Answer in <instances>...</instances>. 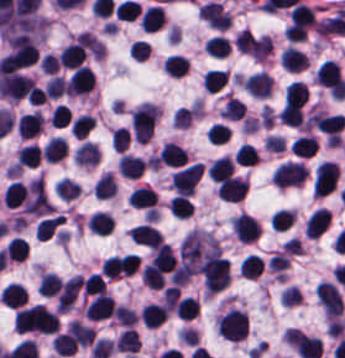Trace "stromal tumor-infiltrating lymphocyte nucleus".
<instances>
[{
	"label": "stromal tumor-infiltrating lymphocyte nucleus",
	"mask_w": 345,
	"mask_h": 358,
	"mask_svg": "<svg viewBox=\"0 0 345 358\" xmlns=\"http://www.w3.org/2000/svg\"><path fill=\"white\" fill-rule=\"evenodd\" d=\"M219 332L230 340L241 341L248 335L247 314L240 309H232L219 319Z\"/></svg>",
	"instance_id": "bc302bb0"
},
{
	"label": "stromal tumor-infiltrating lymphocyte nucleus",
	"mask_w": 345,
	"mask_h": 358,
	"mask_svg": "<svg viewBox=\"0 0 345 358\" xmlns=\"http://www.w3.org/2000/svg\"><path fill=\"white\" fill-rule=\"evenodd\" d=\"M156 115L154 104L142 103L134 112L131 118L133 138L146 142L153 132Z\"/></svg>",
	"instance_id": "52c7bb5b"
},
{
	"label": "stromal tumor-infiltrating lymphocyte nucleus",
	"mask_w": 345,
	"mask_h": 358,
	"mask_svg": "<svg viewBox=\"0 0 345 358\" xmlns=\"http://www.w3.org/2000/svg\"><path fill=\"white\" fill-rule=\"evenodd\" d=\"M204 170L205 166L200 163L179 169L172 179L177 195H192Z\"/></svg>",
	"instance_id": "3290ff9b"
},
{
	"label": "stromal tumor-infiltrating lymphocyte nucleus",
	"mask_w": 345,
	"mask_h": 358,
	"mask_svg": "<svg viewBox=\"0 0 345 358\" xmlns=\"http://www.w3.org/2000/svg\"><path fill=\"white\" fill-rule=\"evenodd\" d=\"M307 173L300 163L289 160L277 166L272 182L278 187L295 186L304 181Z\"/></svg>",
	"instance_id": "abfb95fc"
},
{
	"label": "stromal tumor-infiltrating lymphocyte nucleus",
	"mask_w": 345,
	"mask_h": 358,
	"mask_svg": "<svg viewBox=\"0 0 345 358\" xmlns=\"http://www.w3.org/2000/svg\"><path fill=\"white\" fill-rule=\"evenodd\" d=\"M318 301L325 312L339 316L342 311V297L334 283L322 281L315 289Z\"/></svg>",
	"instance_id": "9ea309e8"
},
{
	"label": "stromal tumor-infiltrating lymphocyte nucleus",
	"mask_w": 345,
	"mask_h": 358,
	"mask_svg": "<svg viewBox=\"0 0 345 358\" xmlns=\"http://www.w3.org/2000/svg\"><path fill=\"white\" fill-rule=\"evenodd\" d=\"M116 312V304L109 294L98 293L87 304L85 315L89 319H102Z\"/></svg>",
	"instance_id": "f3e2335f"
},
{
	"label": "stromal tumor-infiltrating lymphocyte nucleus",
	"mask_w": 345,
	"mask_h": 358,
	"mask_svg": "<svg viewBox=\"0 0 345 358\" xmlns=\"http://www.w3.org/2000/svg\"><path fill=\"white\" fill-rule=\"evenodd\" d=\"M232 227L241 241H254L262 232L261 227L251 215L241 214L234 217Z\"/></svg>",
	"instance_id": "4f13568d"
},
{
	"label": "stromal tumor-infiltrating lymphocyte nucleus",
	"mask_w": 345,
	"mask_h": 358,
	"mask_svg": "<svg viewBox=\"0 0 345 358\" xmlns=\"http://www.w3.org/2000/svg\"><path fill=\"white\" fill-rule=\"evenodd\" d=\"M273 80L266 71H258L246 77L244 86L251 95L266 97L271 95Z\"/></svg>",
	"instance_id": "2a367800"
},
{
	"label": "stromal tumor-infiltrating lymphocyte nucleus",
	"mask_w": 345,
	"mask_h": 358,
	"mask_svg": "<svg viewBox=\"0 0 345 358\" xmlns=\"http://www.w3.org/2000/svg\"><path fill=\"white\" fill-rule=\"evenodd\" d=\"M129 237L131 241L153 248L163 242L161 232L147 223H139L129 228Z\"/></svg>",
	"instance_id": "4803ca6d"
},
{
	"label": "stromal tumor-infiltrating lymphocyte nucleus",
	"mask_w": 345,
	"mask_h": 358,
	"mask_svg": "<svg viewBox=\"0 0 345 358\" xmlns=\"http://www.w3.org/2000/svg\"><path fill=\"white\" fill-rule=\"evenodd\" d=\"M248 185L245 180L239 177L230 176L220 183L218 195L226 201H239L247 192Z\"/></svg>",
	"instance_id": "4245b91a"
},
{
	"label": "stromal tumor-infiltrating lymphocyte nucleus",
	"mask_w": 345,
	"mask_h": 358,
	"mask_svg": "<svg viewBox=\"0 0 345 358\" xmlns=\"http://www.w3.org/2000/svg\"><path fill=\"white\" fill-rule=\"evenodd\" d=\"M128 205L155 213L156 195L152 187L139 186L127 198Z\"/></svg>",
	"instance_id": "4c9ddf68"
},
{
	"label": "stromal tumor-infiltrating lymphocyte nucleus",
	"mask_w": 345,
	"mask_h": 358,
	"mask_svg": "<svg viewBox=\"0 0 345 358\" xmlns=\"http://www.w3.org/2000/svg\"><path fill=\"white\" fill-rule=\"evenodd\" d=\"M331 212L326 207H319L309 218L306 226V234L319 237L330 224Z\"/></svg>",
	"instance_id": "2761f720"
},
{
	"label": "stromal tumor-infiltrating lymphocyte nucleus",
	"mask_w": 345,
	"mask_h": 358,
	"mask_svg": "<svg viewBox=\"0 0 345 358\" xmlns=\"http://www.w3.org/2000/svg\"><path fill=\"white\" fill-rule=\"evenodd\" d=\"M4 305L19 308L28 300V293L21 283H8L0 296Z\"/></svg>",
	"instance_id": "3c572f05"
},
{
	"label": "stromal tumor-infiltrating lymphocyte nucleus",
	"mask_w": 345,
	"mask_h": 358,
	"mask_svg": "<svg viewBox=\"0 0 345 358\" xmlns=\"http://www.w3.org/2000/svg\"><path fill=\"white\" fill-rule=\"evenodd\" d=\"M282 66L289 71H303L309 63L308 55L298 50L294 46H289L282 51Z\"/></svg>",
	"instance_id": "42bb06b2"
},
{
	"label": "stromal tumor-infiltrating lymphocyte nucleus",
	"mask_w": 345,
	"mask_h": 358,
	"mask_svg": "<svg viewBox=\"0 0 345 358\" xmlns=\"http://www.w3.org/2000/svg\"><path fill=\"white\" fill-rule=\"evenodd\" d=\"M86 56L85 47L78 42H71L59 56L60 66L77 68Z\"/></svg>",
	"instance_id": "9e4306bb"
},
{
	"label": "stromal tumor-infiltrating lymphocyte nucleus",
	"mask_w": 345,
	"mask_h": 358,
	"mask_svg": "<svg viewBox=\"0 0 345 358\" xmlns=\"http://www.w3.org/2000/svg\"><path fill=\"white\" fill-rule=\"evenodd\" d=\"M186 161V155L180 145L174 142H167L163 145L159 156L158 164L183 166Z\"/></svg>",
	"instance_id": "04cf8593"
},
{
	"label": "stromal tumor-infiltrating lymphocyte nucleus",
	"mask_w": 345,
	"mask_h": 358,
	"mask_svg": "<svg viewBox=\"0 0 345 358\" xmlns=\"http://www.w3.org/2000/svg\"><path fill=\"white\" fill-rule=\"evenodd\" d=\"M143 324L146 326H159L164 323L168 316L166 305L148 303L141 311Z\"/></svg>",
	"instance_id": "e9af9c67"
},
{
	"label": "stromal tumor-infiltrating lymphocyte nucleus",
	"mask_w": 345,
	"mask_h": 358,
	"mask_svg": "<svg viewBox=\"0 0 345 358\" xmlns=\"http://www.w3.org/2000/svg\"><path fill=\"white\" fill-rule=\"evenodd\" d=\"M144 166L145 160L130 154H123L119 160L118 169L121 174L128 177H140L143 175Z\"/></svg>",
	"instance_id": "782c7336"
},
{
	"label": "stromal tumor-infiltrating lymphocyte nucleus",
	"mask_w": 345,
	"mask_h": 358,
	"mask_svg": "<svg viewBox=\"0 0 345 358\" xmlns=\"http://www.w3.org/2000/svg\"><path fill=\"white\" fill-rule=\"evenodd\" d=\"M318 146V138L314 135L303 134L293 140L291 150L294 155L310 157L314 155Z\"/></svg>",
	"instance_id": "cac63f63"
},
{
	"label": "stromal tumor-infiltrating lymphocyte nucleus",
	"mask_w": 345,
	"mask_h": 358,
	"mask_svg": "<svg viewBox=\"0 0 345 358\" xmlns=\"http://www.w3.org/2000/svg\"><path fill=\"white\" fill-rule=\"evenodd\" d=\"M164 12L160 5H153L143 11L141 15V26L146 32H154L159 28L164 19Z\"/></svg>",
	"instance_id": "2e467ee5"
},
{
	"label": "stromal tumor-infiltrating lymphocyte nucleus",
	"mask_w": 345,
	"mask_h": 358,
	"mask_svg": "<svg viewBox=\"0 0 345 358\" xmlns=\"http://www.w3.org/2000/svg\"><path fill=\"white\" fill-rule=\"evenodd\" d=\"M101 153L92 140H85L75 152V161L81 164H97Z\"/></svg>",
	"instance_id": "7eef579d"
},
{
	"label": "stromal tumor-infiltrating lymphocyte nucleus",
	"mask_w": 345,
	"mask_h": 358,
	"mask_svg": "<svg viewBox=\"0 0 345 358\" xmlns=\"http://www.w3.org/2000/svg\"><path fill=\"white\" fill-rule=\"evenodd\" d=\"M27 195L28 191L25 184L14 180L4 190V205L15 207L24 201Z\"/></svg>",
	"instance_id": "c26a33f6"
},
{
	"label": "stromal tumor-infiltrating lymphocyte nucleus",
	"mask_w": 345,
	"mask_h": 358,
	"mask_svg": "<svg viewBox=\"0 0 345 358\" xmlns=\"http://www.w3.org/2000/svg\"><path fill=\"white\" fill-rule=\"evenodd\" d=\"M40 131V114L28 112L19 116V135L32 137Z\"/></svg>",
	"instance_id": "3e0999b9"
},
{
	"label": "stromal tumor-infiltrating lymphocyte nucleus",
	"mask_w": 345,
	"mask_h": 358,
	"mask_svg": "<svg viewBox=\"0 0 345 358\" xmlns=\"http://www.w3.org/2000/svg\"><path fill=\"white\" fill-rule=\"evenodd\" d=\"M309 99V86L304 82L292 81L286 91V100L304 106Z\"/></svg>",
	"instance_id": "a0a3295f"
},
{
	"label": "stromal tumor-infiltrating lymphocyte nucleus",
	"mask_w": 345,
	"mask_h": 358,
	"mask_svg": "<svg viewBox=\"0 0 345 358\" xmlns=\"http://www.w3.org/2000/svg\"><path fill=\"white\" fill-rule=\"evenodd\" d=\"M29 246L24 237L14 236L5 246L4 254L10 260L22 261Z\"/></svg>",
	"instance_id": "b6af03f8"
},
{
	"label": "stromal tumor-infiltrating lymphocyte nucleus",
	"mask_w": 345,
	"mask_h": 358,
	"mask_svg": "<svg viewBox=\"0 0 345 358\" xmlns=\"http://www.w3.org/2000/svg\"><path fill=\"white\" fill-rule=\"evenodd\" d=\"M235 165L230 156H222L209 166L208 172L213 179L225 180L232 175Z\"/></svg>",
	"instance_id": "6c763739"
},
{
	"label": "stromal tumor-infiltrating lymphocyte nucleus",
	"mask_w": 345,
	"mask_h": 358,
	"mask_svg": "<svg viewBox=\"0 0 345 358\" xmlns=\"http://www.w3.org/2000/svg\"><path fill=\"white\" fill-rule=\"evenodd\" d=\"M153 259L160 266L164 273L173 268L175 264V256L170 246L166 243L160 242L154 248Z\"/></svg>",
	"instance_id": "fa64b396"
},
{
	"label": "stromal tumor-infiltrating lymphocyte nucleus",
	"mask_w": 345,
	"mask_h": 358,
	"mask_svg": "<svg viewBox=\"0 0 345 358\" xmlns=\"http://www.w3.org/2000/svg\"><path fill=\"white\" fill-rule=\"evenodd\" d=\"M19 166H36L40 161V147L36 143H29L19 148L17 152Z\"/></svg>",
	"instance_id": "21d57d70"
},
{
	"label": "stromal tumor-infiltrating lymphocyte nucleus",
	"mask_w": 345,
	"mask_h": 358,
	"mask_svg": "<svg viewBox=\"0 0 345 358\" xmlns=\"http://www.w3.org/2000/svg\"><path fill=\"white\" fill-rule=\"evenodd\" d=\"M88 227L97 234H107L112 228V217L102 211H95L91 214L88 222Z\"/></svg>",
	"instance_id": "02f42fee"
},
{
	"label": "stromal tumor-infiltrating lymphocyte nucleus",
	"mask_w": 345,
	"mask_h": 358,
	"mask_svg": "<svg viewBox=\"0 0 345 358\" xmlns=\"http://www.w3.org/2000/svg\"><path fill=\"white\" fill-rule=\"evenodd\" d=\"M78 343L75 336L69 331L56 335L53 341V347L58 355H71Z\"/></svg>",
	"instance_id": "18da8d3c"
},
{
	"label": "stromal tumor-infiltrating lymphocyte nucleus",
	"mask_w": 345,
	"mask_h": 358,
	"mask_svg": "<svg viewBox=\"0 0 345 358\" xmlns=\"http://www.w3.org/2000/svg\"><path fill=\"white\" fill-rule=\"evenodd\" d=\"M63 215H54L51 217L43 218L36 223L35 233L39 239L47 240L52 236L56 228L59 226Z\"/></svg>",
	"instance_id": "8379cbfb"
},
{
	"label": "stromal tumor-infiltrating lymphocyte nucleus",
	"mask_w": 345,
	"mask_h": 358,
	"mask_svg": "<svg viewBox=\"0 0 345 358\" xmlns=\"http://www.w3.org/2000/svg\"><path fill=\"white\" fill-rule=\"evenodd\" d=\"M140 345L137 330L126 328L117 339L116 350L135 352Z\"/></svg>",
	"instance_id": "023d44f5"
},
{
	"label": "stromal tumor-infiltrating lymphocyte nucleus",
	"mask_w": 345,
	"mask_h": 358,
	"mask_svg": "<svg viewBox=\"0 0 345 358\" xmlns=\"http://www.w3.org/2000/svg\"><path fill=\"white\" fill-rule=\"evenodd\" d=\"M65 154L66 139L54 135L44 144V156L50 161H57Z\"/></svg>",
	"instance_id": "afbf053c"
},
{
	"label": "stromal tumor-infiltrating lymphocyte nucleus",
	"mask_w": 345,
	"mask_h": 358,
	"mask_svg": "<svg viewBox=\"0 0 345 358\" xmlns=\"http://www.w3.org/2000/svg\"><path fill=\"white\" fill-rule=\"evenodd\" d=\"M69 331L76 342L82 345H90L96 335L91 326L73 320L70 321Z\"/></svg>",
	"instance_id": "1d375fb5"
},
{
	"label": "stromal tumor-infiltrating lymphocyte nucleus",
	"mask_w": 345,
	"mask_h": 358,
	"mask_svg": "<svg viewBox=\"0 0 345 358\" xmlns=\"http://www.w3.org/2000/svg\"><path fill=\"white\" fill-rule=\"evenodd\" d=\"M188 60L180 54L168 56L164 62V69L170 76H183L188 67Z\"/></svg>",
	"instance_id": "84afeb40"
},
{
	"label": "stromal tumor-infiltrating lymphocyte nucleus",
	"mask_w": 345,
	"mask_h": 358,
	"mask_svg": "<svg viewBox=\"0 0 345 358\" xmlns=\"http://www.w3.org/2000/svg\"><path fill=\"white\" fill-rule=\"evenodd\" d=\"M116 189L112 173H105L97 179L92 188L93 196L108 197L113 196Z\"/></svg>",
	"instance_id": "a6e9041d"
},
{
	"label": "stromal tumor-infiltrating lymphocyte nucleus",
	"mask_w": 345,
	"mask_h": 358,
	"mask_svg": "<svg viewBox=\"0 0 345 358\" xmlns=\"http://www.w3.org/2000/svg\"><path fill=\"white\" fill-rule=\"evenodd\" d=\"M142 279L149 288L158 289L164 283L163 273L153 261L143 267Z\"/></svg>",
	"instance_id": "83f04bf1"
},
{
	"label": "stromal tumor-infiltrating lymphocyte nucleus",
	"mask_w": 345,
	"mask_h": 358,
	"mask_svg": "<svg viewBox=\"0 0 345 358\" xmlns=\"http://www.w3.org/2000/svg\"><path fill=\"white\" fill-rule=\"evenodd\" d=\"M281 122L300 125L304 119L303 111L298 104L286 103L283 105L280 113Z\"/></svg>",
	"instance_id": "16295066"
},
{
	"label": "stromal tumor-infiltrating lymphocyte nucleus",
	"mask_w": 345,
	"mask_h": 358,
	"mask_svg": "<svg viewBox=\"0 0 345 358\" xmlns=\"http://www.w3.org/2000/svg\"><path fill=\"white\" fill-rule=\"evenodd\" d=\"M60 286L61 278L59 274L50 271L43 273L39 281L38 289L45 295H54L59 291Z\"/></svg>",
	"instance_id": "a33fdf23"
},
{
	"label": "stromal tumor-infiltrating lymphocyte nucleus",
	"mask_w": 345,
	"mask_h": 358,
	"mask_svg": "<svg viewBox=\"0 0 345 358\" xmlns=\"http://www.w3.org/2000/svg\"><path fill=\"white\" fill-rule=\"evenodd\" d=\"M205 48L211 55L227 56L231 49V41L225 36L213 35Z\"/></svg>",
	"instance_id": "c8d0df70"
},
{
	"label": "stromal tumor-infiltrating lymphocyte nucleus",
	"mask_w": 345,
	"mask_h": 358,
	"mask_svg": "<svg viewBox=\"0 0 345 358\" xmlns=\"http://www.w3.org/2000/svg\"><path fill=\"white\" fill-rule=\"evenodd\" d=\"M95 119L92 114H79L70 130L76 138H85L91 130Z\"/></svg>",
	"instance_id": "7b516f1d"
},
{
	"label": "stromal tumor-infiltrating lymphocyte nucleus",
	"mask_w": 345,
	"mask_h": 358,
	"mask_svg": "<svg viewBox=\"0 0 345 358\" xmlns=\"http://www.w3.org/2000/svg\"><path fill=\"white\" fill-rule=\"evenodd\" d=\"M173 215L179 217L191 216L194 212L191 202L186 196L176 195L169 201Z\"/></svg>",
	"instance_id": "ccc9de39"
},
{
	"label": "stromal tumor-infiltrating lymphocyte nucleus",
	"mask_w": 345,
	"mask_h": 358,
	"mask_svg": "<svg viewBox=\"0 0 345 358\" xmlns=\"http://www.w3.org/2000/svg\"><path fill=\"white\" fill-rule=\"evenodd\" d=\"M227 80L226 72L222 70H209L205 74L204 83L208 92H216L225 86Z\"/></svg>",
	"instance_id": "50b3126c"
},
{
	"label": "stromal tumor-infiltrating lymphocyte nucleus",
	"mask_w": 345,
	"mask_h": 358,
	"mask_svg": "<svg viewBox=\"0 0 345 358\" xmlns=\"http://www.w3.org/2000/svg\"><path fill=\"white\" fill-rule=\"evenodd\" d=\"M245 108H246V103H244L237 97L230 96L225 103V106L222 111V115L225 118L241 119Z\"/></svg>",
	"instance_id": "6da75f8f"
},
{
	"label": "stromal tumor-infiltrating lymphocyte nucleus",
	"mask_w": 345,
	"mask_h": 358,
	"mask_svg": "<svg viewBox=\"0 0 345 358\" xmlns=\"http://www.w3.org/2000/svg\"><path fill=\"white\" fill-rule=\"evenodd\" d=\"M55 190L59 196L69 200L78 196L81 191L79 185L70 178H62L58 181Z\"/></svg>",
	"instance_id": "fc20714e"
},
{
	"label": "stromal tumor-infiltrating lymphocyte nucleus",
	"mask_w": 345,
	"mask_h": 358,
	"mask_svg": "<svg viewBox=\"0 0 345 358\" xmlns=\"http://www.w3.org/2000/svg\"><path fill=\"white\" fill-rule=\"evenodd\" d=\"M178 315L183 319H191L196 316L199 311V303L196 298L186 296L181 300L177 307Z\"/></svg>",
	"instance_id": "894b7857"
},
{
	"label": "stromal tumor-infiltrating lymphocyte nucleus",
	"mask_w": 345,
	"mask_h": 358,
	"mask_svg": "<svg viewBox=\"0 0 345 358\" xmlns=\"http://www.w3.org/2000/svg\"><path fill=\"white\" fill-rule=\"evenodd\" d=\"M230 137V127L227 124L214 123L209 129L208 139L213 144H222L230 140Z\"/></svg>",
	"instance_id": "fb6c686a"
},
{
	"label": "stromal tumor-infiltrating lymphocyte nucleus",
	"mask_w": 345,
	"mask_h": 358,
	"mask_svg": "<svg viewBox=\"0 0 345 358\" xmlns=\"http://www.w3.org/2000/svg\"><path fill=\"white\" fill-rule=\"evenodd\" d=\"M294 211L287 209H279L272 217L271 223L273 227L285 230L293 221Z\"/></svg>",
	"instance_id": "a5eb4a43"
}]
</instances>
